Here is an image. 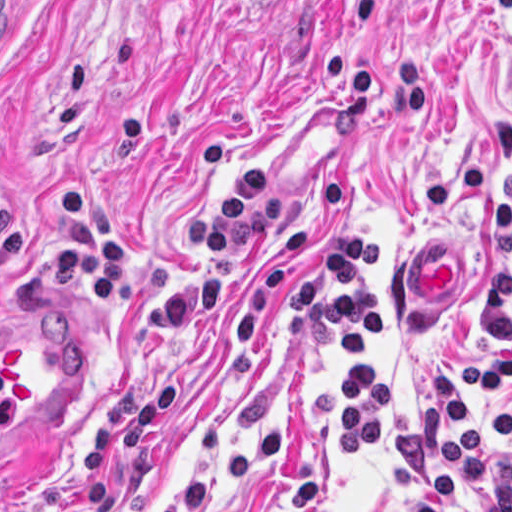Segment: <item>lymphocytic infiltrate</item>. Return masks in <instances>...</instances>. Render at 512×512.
Wrapping results in <instances>:
<instances>
[{
    "label": "lymphocytic infiltrate",
    "mask_w": 512,
    "mask_h": 512,
    "mask_svg": "<svg viewBox=\"0 0 512 512\" xmlns=\"http://www.w3.org/2000/svg\"><path fill=\"white\" fill-rule=\"evenodd\" d=\"M383 261V229L344 224L323 234L272 296L282 323L339 336L337 433L352 476L374 468L387 439V383L369 347L387 331ZM486 264L479 326L487 339L475 336L471 355L433 376L421 413L391 443L422 494L413 512H512V223L486 234Z\"/></svg>",
    "instance_id": "1"
}]
</instances>
